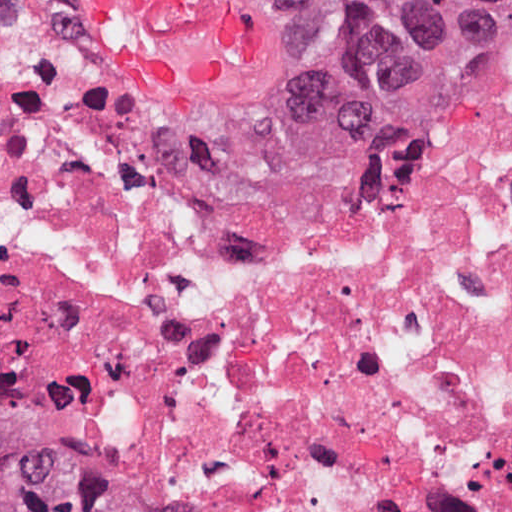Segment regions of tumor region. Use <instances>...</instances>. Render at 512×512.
I'll use <instances>...</instances> for the list:
<instances>
[{
	"instance_id": "tumor-region-1",
	"label": "tumor region",
	"mask_w": 512,
	"mask_h": 512,
	"mask_svg": "<svg viewBox=\"0 0 512 512\" xmlns=\"http://www.w3.org/2000/svg\"><path fill=\"white\" fill-rule=\"evenodd\" d=\"M343 136L392 153L457 124L512 58V0H311ZM0 512H202L0 311Z\"/></svg>"
}]
</instances>
